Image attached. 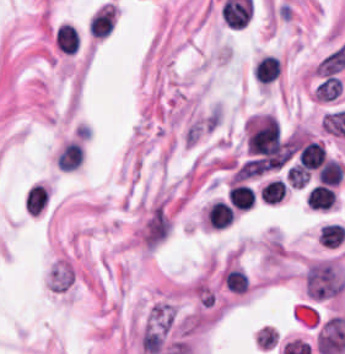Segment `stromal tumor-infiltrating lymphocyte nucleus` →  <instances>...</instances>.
Instances as JSON below:
<instances>
[{
    "mask_svg": "<svg viewBox=\"0 0 345 354\" xmlns=\"http://www.w3.org/2000/svg\"><path fill=\"white\" fill-rule=\"evenodd\" d=\"M279 71V60L270 55H263L254 64V80L261 83H269L274 80Z\"/></svg>",
    "mask_w": 345,
    "mask_h": 354,
    "instance_id": "obj_1",
    "label": "stromal tumor-infiltrating lymphocyte nucleus"
},
{
    "mask_svg": "<svg viewBox=\"0 0 345 354\" xmlns=\"http://www.w3.org/2000/svg\"><path fill=\"white\" fill-rule=\"evenodd\" d=\"M47 188L33 184L25 195V208L30 215H39L47 205Z\"/></svg>",
    "mask_w": 345,
    "mask_h": 354,
    "instance_id": "obj_2",
    "label": "stromal tumor-infiltrating lymphocyte nucleus"
}]
</instances>
